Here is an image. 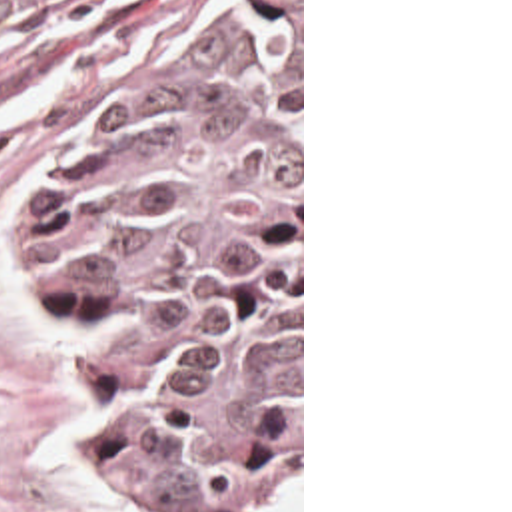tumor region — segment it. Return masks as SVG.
Listing matches in <instances>:
<instances>
[{
	"mask_svg": "<svg viewBox=\"0 0 512 512\" xmlns=\"http://www.w3.org/2000/svg\"><path fill=\"white\" fill-rule=\"evenodd\" d=\"M70 0H0V41ZM106 467L270 512L300 461V0H252L94 113L32 213Z\"/></svg>",
	"mask_w": 512,
	"mask_h": 512,
	"instance_id": "1",
	"label": "tumor region"
}]
</instances>
